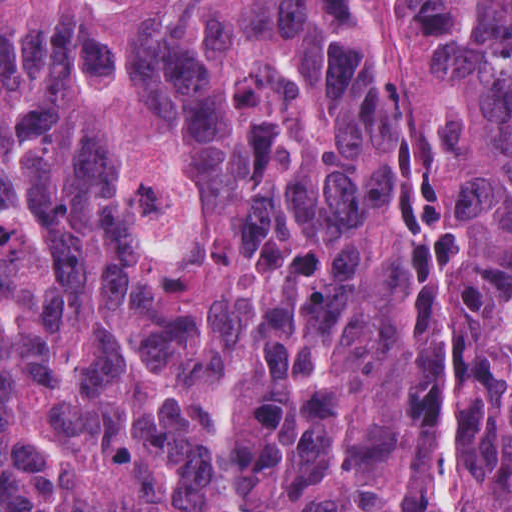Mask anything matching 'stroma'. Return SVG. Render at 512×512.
<instances>
[{
	"label": "stroma",
	"mask_w": 512,
	"mask_h": 512,
	"mask_svg": "<svg viewBox=\"0 0 512 512\" xmlns=\"http://www.w3.org/2000/svg\"><path fill=\"white\" fill-rule=\"evenodd\" d=\"M379 47L393 78L399 101L407 115L412 112L411 74L402 36V0H362ZM0 512H1V0H0Z\"/></svg>",
	"instance_id": "1"
}]
</instances>
